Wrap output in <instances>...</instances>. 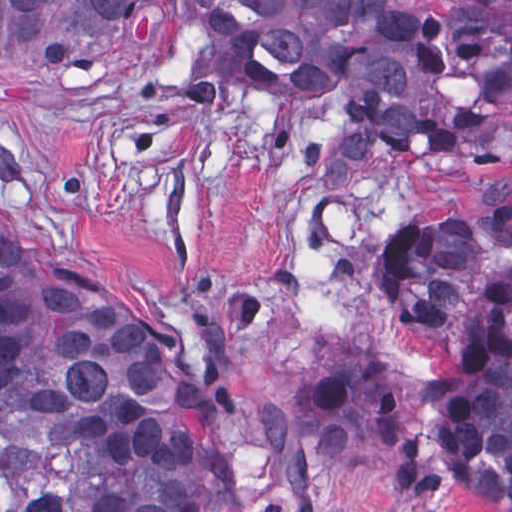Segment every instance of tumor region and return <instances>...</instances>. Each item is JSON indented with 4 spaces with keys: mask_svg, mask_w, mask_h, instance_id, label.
<instances>
[{
    "mask_svg": "<svg viewBox=\"0 0 512 512\" xmlns=\"http://www.w3.org/2000/svg\"><path fill=\"white\" fill-rule=\"evenodd\" d=\"M241 84L332 100L313 179L366 162L512 149V14L422 0H0V82L54 86L182 19ZM385 313L433 373L358 358L309 379L299 421L405 512L448 488L512 512V185L374 246ZM399 332V323L390 321ZM230 484L213 404L83 281L65 220L0 210V512H210Z\"/></svg>",
    "mask_w": 512,
    "mask_h": 512,
    "instance_id": "tumor-region-1",
    "label": "tumor region"
}]
</instances>
